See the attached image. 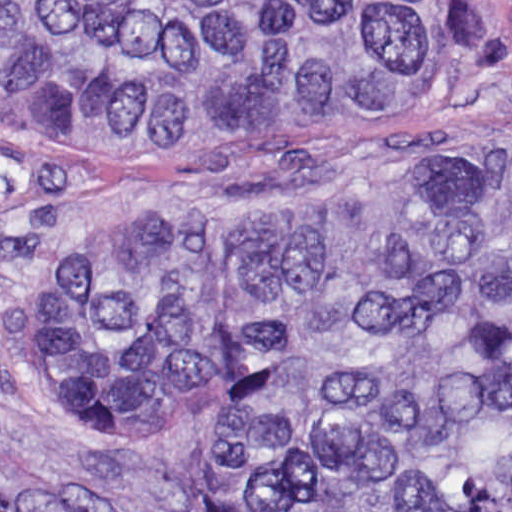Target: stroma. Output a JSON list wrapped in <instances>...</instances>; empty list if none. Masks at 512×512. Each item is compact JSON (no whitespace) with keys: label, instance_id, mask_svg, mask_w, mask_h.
I'll use <instances>...</instances> for the list:
<instances>
[{"label":"stroma","instance_id":"stroma-1","mask_svg":"<svg viewBox=\"0 0 512 512\" xmlns=\"http://www.w3.org/2000/svg\"><path fill=\"white\" fill-rule=\"evenodd\" d=\"M499 40L466 84L335 130L245 144L54 147L0 129V512H213V420L136 451L74 439L31 347L42 279L103 213H258L444 171L512 144V0H465Z\"/></svg>","mask_w":512,"mask_h":512}]
</instances>
